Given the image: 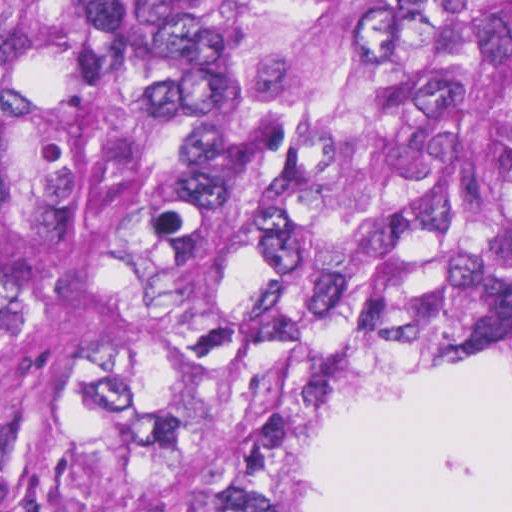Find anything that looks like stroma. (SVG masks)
Returning a JSON list of instances; mask_svg holds the SVG:
<instances>
[{
  "mask_svg": "<svg viewBox=\"0 0 512 512\" xmlns=\"http://www.w3.org/2000/svg\"><path fill=\"white\" fill-rule=\"evenodd\" d=\"M386 382H371L368 384L365 388H363L359 393H357L354 397H352L349 402L345 405V407L340 411V413L336 416V418L333 420L332 424L328 428L327 432L323 436L321 440V465L319 467L318 473L316 475L315 481L313 483L309 503L306 512L310 511L312 502L314 500L322 472L325 466V463L327 461V458L341 432L344 425L346 424L348 418L350 417L351 413L354 411V409L357 407V405L360 403V401L363 399V397L373 391L374 389L378 388L382 384Z\"/></svg>",
  "mask_w": 512,
  "mask_h": 512,
  "instance_id": "35a3bbf8",
  "label": "stroma"
}]
</instances>
